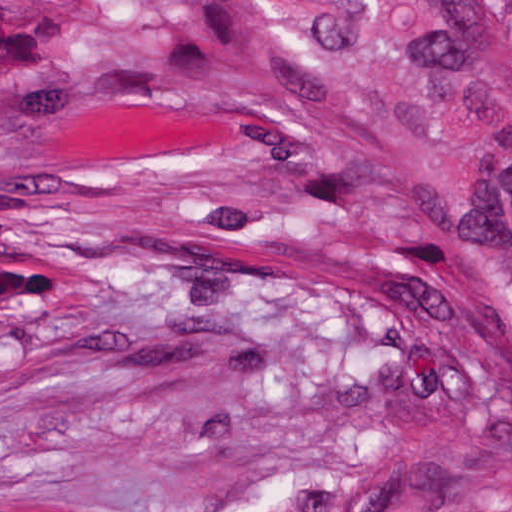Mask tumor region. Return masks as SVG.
Instances as JSON below:
<instances>
[{"label": "tumor region", "instance_id": "1", "mask_svg": "<svg viewBox=\"0 0 512 512\" xmlns=\"http://www.w3.org/2000/svg\"><path fill=\"white\" fill-rule=\"evenodd\" d=\"M203 3L254 100L428 225L385 512H512V0Z\"/></svg>", "mask_w": 512, "mask_h": 512}]
</instances>
